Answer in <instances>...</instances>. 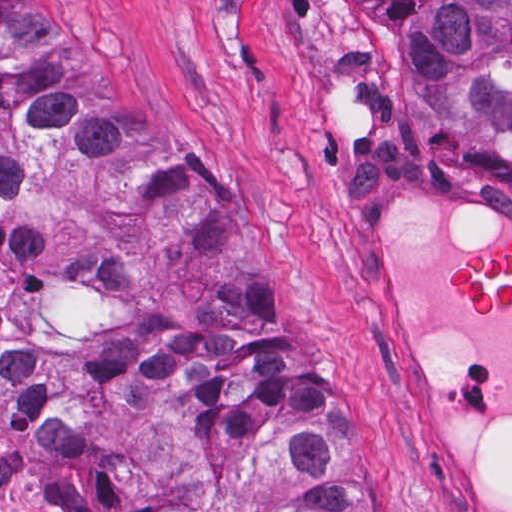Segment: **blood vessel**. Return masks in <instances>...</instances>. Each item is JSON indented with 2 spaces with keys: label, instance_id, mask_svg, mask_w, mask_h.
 I'll use <instances>...</instances> for the list:
<instances>
[{
  "label": "blood vessel",
  "instance_id": "obj_1",
  "mask_svg": "<svg viewBox=\"0 0 512 512\" xmlns=\"http://www.w3.org/2000/svg\"><path fill=\"white\" fill-rule=\"evenodd\" d=\"M368 328L406 462L439 512H512V204L427 158L356 192Z\"/></svg>",
  "mask_w": 512,
  "mask_h": 512
}]
</instances>
